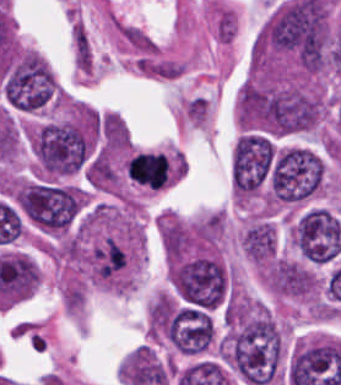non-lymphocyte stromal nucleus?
<instances>
[{
    "label": "non-lymphocyte stromal nucleus",
    "instance_id": "dd21d789",
    "mask_svg": "<svg viewBox=\"0 0 341 385\" xmlns=\"http://www.w3.org/2000/svg\"><path fill=\"white\" fill-rule=\"evenodd\" d=\"M72 44L75 63L78 70L91 71L93 60L89 39L83 24H76L72 32Z\"/></svg>",
    "mask_w": 341,
    "mask_h": 385
},
{
    "label": "non-lymphocyte stromal nucleus",
    "instance_id": "a72fc3eb",
    "mask_svg": "<svg viewBox=\"0 0 341 385\" xmlns=\"http://www.w3.org/2000/svg\"><path fill=\"white\" fill-rule=\"evenodd\" d=\"M117 31L124 41L129 43L139 52H154V41L139 27L121 24Z\"/></svg>",
    "mask_w": 341,
    "mask_h": 385
}]
</instances>
